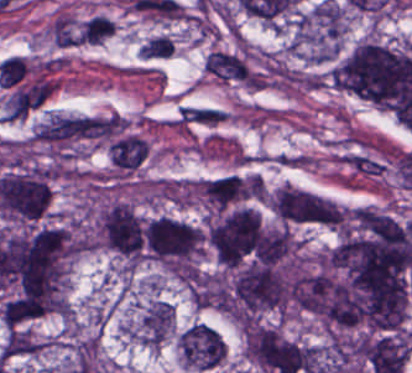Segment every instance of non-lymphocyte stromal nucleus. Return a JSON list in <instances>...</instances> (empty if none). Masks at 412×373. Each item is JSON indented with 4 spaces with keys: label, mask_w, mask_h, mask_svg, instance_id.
Wrapping results in <instances>:
<instances>
[{
    "label": "non-lymphocyte stromal nucleus",
    "mask_w": 412,
    "mask_h": 373,
    "mask_svg": "<svg viewBox=\"0 0 412 373\" xmlns=\"http://www.w3.org/2000/svg\"><path fill=\"white\" fill-rule=\"evenodd\" d=\"M205 70L227 80L243 79L249 73L247 63L242 58L221 50H214L207 55Z\"/></svg>",
    "instance_id": "1"
},
{
    "label": "non-lymphocyte stromal nucleus",
    "mask_w": 412,
    "mask_h": 373,
    "mask_svg": "<svg viewBox=\"0 0 412 373\" xmlns=\"http://www.w3.org/2000/svg\"><path fill=\"white\" fill-rule=\"evenodd\" d=\"M50 36L57 46H74L79 43L78 30L73 17L67 11H59L50 26Z\"/></svg>",
    "instance_id": "2"
},
{
    "label": "non-lymphocyte stromal nucleus",
    "mask_w": 412,
    "mask_h": 373,
    "mask_svg": "<svg viewBox=\"0 0 412 373\" xmlns=\"http://www.w3.org/2000/svg\"><path fill=\"white\" fill-rule=\"evenodd\" d=\"M226 112L210 105H184L176 119L185 124H216L221 121Z\"/></svg>",
    "instance_id": "3"
},
{
    "label": "non-lymphocyte stromal nucleus",
    "mask_w": 412,
    "mask_h": 373,
    "mask_svg": "<svg viewBox=\"0 0 412 373\" xmlns=\"http://www.w3.org/2000/svg\"><path fill=\"white\" fill-rule=\"evenodd\" d=\"M174 38L166 33L149 37L139 46V52L144 57L160 58L172 53Z\"/></svg>",
    "instance_id": "4"
}]
</instances>
